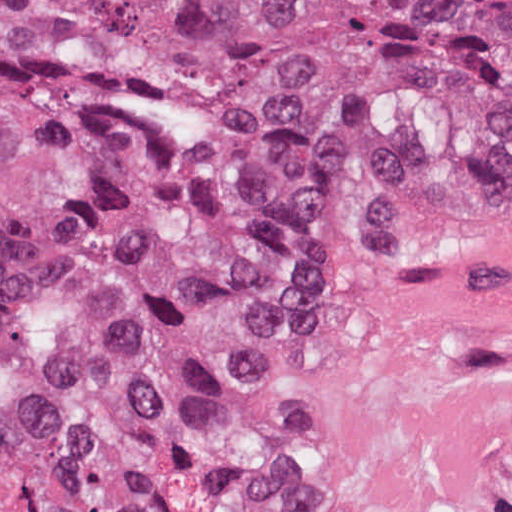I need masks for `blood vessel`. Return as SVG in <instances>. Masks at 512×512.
<instances>
[{"mask_svg": "<svg viewBox=\"0 0 512 512\" xmlns=\"http://www.w3.org/2000/svg\"><path fill=\"white\" fill-rule=\"evenodd\" d=\"M290 512H512V196L322 270L269 346Z\"/></svg>", "mask_w": 512, "mask_h": 512, "instance_id": "obj_1", "label": "blood vessel"}]
</instances>
